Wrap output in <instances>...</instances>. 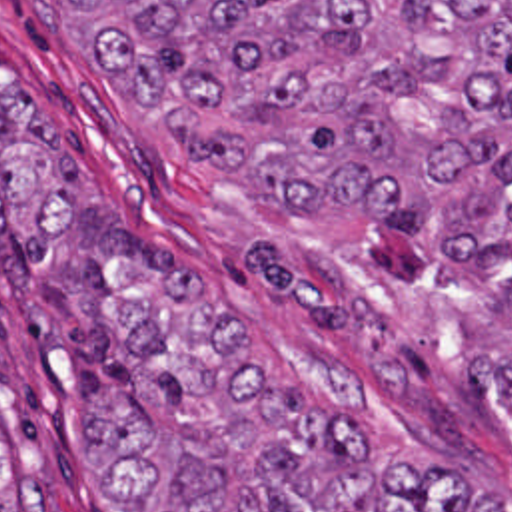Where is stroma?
<instances>
[{
    "mask_svg": "<svg viewBox=\"0 0 512 512\" xmlns=\"http://www.w3.org/2000/svg\"><path fill=\"white\" fill-rule=\"evenodd\" d=\"M38 102L144 244L182 246L240 361L274 389L374 421L422 459L512 491V387L470 326L378 244L278 218L226 144L76 44L68 0H0V114ZM140 409L0 198V491L44 481L48 512H118L70 447L76 409Z\"/></svg>",
    "mask_w": 512,
    "mask_h": 512,
    "instance_id": "35a3bbf8",
    "label": "stroma"
}]
</instances>
